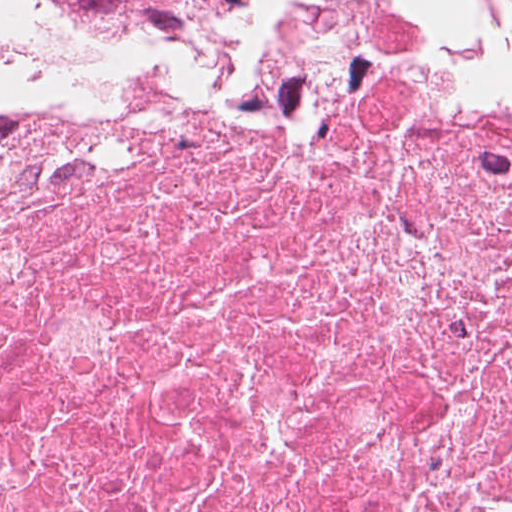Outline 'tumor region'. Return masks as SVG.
Masks as SVG:
<instances>
[{"label":"tumor region","mask_w":512,"mask_h":512,"mask_svg":"<svg viewBox=\"0 0 512 512\" xmlns=\"http://www.w3.org/2000/svg\"><path fill=\"white\" fill-rule=\"evenodd\" d=\"M252 0H0V53L7 52L34 10L92 16L115 24L216 17Z\"/></svg>","instance_id":"1"}]
</instances>
